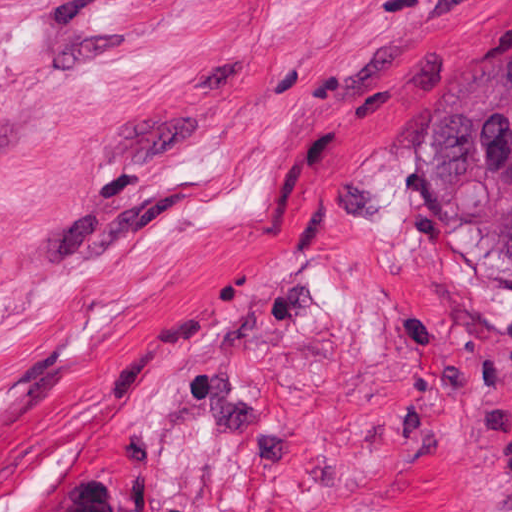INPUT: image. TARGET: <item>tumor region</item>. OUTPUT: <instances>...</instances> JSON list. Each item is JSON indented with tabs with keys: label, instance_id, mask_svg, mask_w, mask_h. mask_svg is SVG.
<instances>
[{
	"label": "tumor region",
	"instance_id": "e687c5a6",
	"mask_svg": "<svg viewBox=\"0 0 512 512\" xmlns=\"http://www.w3.org/2000/svg\"><path fill=\"white\" fill-rule=\"evenodd\" d=\"M423 192L463 278L512 306V37L438 84L423 112ZM501 360L512 379V348ZM501 491L512 512V452Z\"/></svg>",
	"mask_w": 512,
	"mask_h": 512
}]
</instances>
